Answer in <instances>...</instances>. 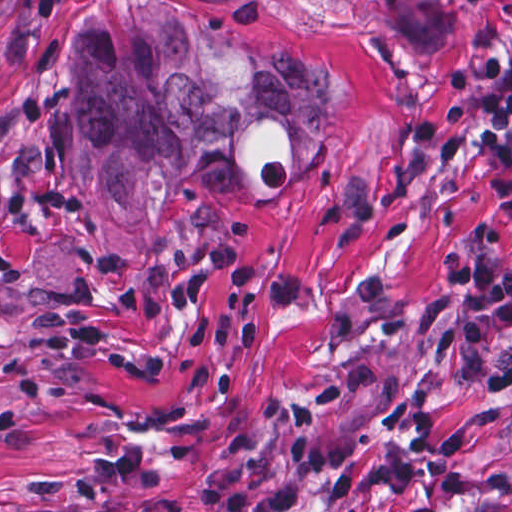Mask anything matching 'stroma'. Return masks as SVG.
Returning <instances> with one entry per match:
<instances>
[{"instance_id": "35a3bbf8", "label": "stroma", "mask_w": 512, "mask_h": 512, "mask_svg": "<svg viewBox=\"0 0 512 512\" xmlns=\"http://www.w3.org/2000/svg\"><path fill=\"white\" fill-rule=\"evenodd\" d=\"M94 0H0V107L36 81L54 30ZM188 4L327 83V147L295 185L171 194L163 258L99 275L88 302L0 321V512L102 498L192 512L211 476L274 478L287 410L338 372L379 382L323 422L355 443L293 512H512V397L452 359L442 262L512 266V154L467 128L446 167L410 123L476 56L512 69V0H155Z\"/></svg>"}]
</instances>
